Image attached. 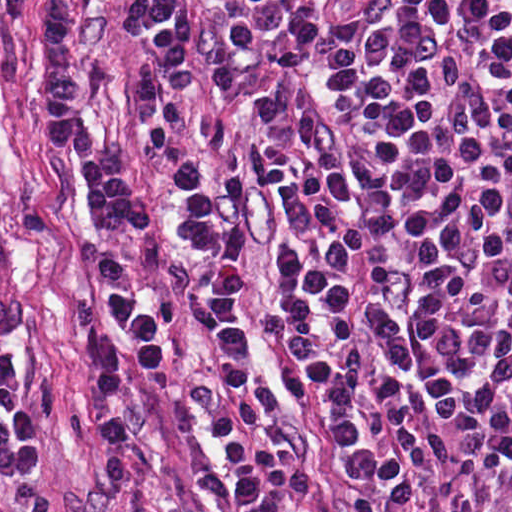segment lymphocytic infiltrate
<instances>
[{"label":"lymphocytic infiltrate","mask_w":512,"mask_h":512,"mask_svg":"<svg viewBox=\"0 0 512 512\" xmlns=\"http://www.w3.org/2000/svg\"><path fill=\"white\" fill-rule=\"evenodd\" d=\"M119 22L126 31L136 28L180 99L196 96L195 0H123ZM35 38V124L47 143L68 156L74 194L96 233L90 232L105 234L124 220L144 234L157 232L158 210L127 161L85 127V44L69 0H40ZM134 65L138 133L172 190L173 234L193 260L189 291L206 325L209 390L234 510L291 512L310 499L314 471L283 427L277 387L256 358L254 307L243 274L252 195L236 171L193 141L186 115L164 80L139 61ZM87 342L95 439L111 454H128L127 336L106 327L91 330Z\"/></svg>","instance_id":"lymphocytic-infiltrate-1"}]
</instances>
